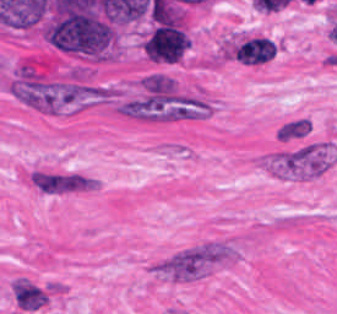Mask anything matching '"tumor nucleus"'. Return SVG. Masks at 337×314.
<instances>
[{
    "mask_svg": "<svg viewBox=\"0 0 337 314\" xmlns=\"http://www.w3.org/2000/svg\"><path fill=\"white\" fill-rule=\"evenodd\" d=\"M190 41L178 24L172 20L162 22L149 36L144 53L158 62H177Z\"/></svg>",
    "mask_w": 337,
    "mask_h": 314,
    "instance_id": "obj_1",
    "label": "tumor nucleus"
},
{
    "mask_svg": "<svg viewBox=\"0 0 337 314\" xmlns=\"http://www.w3.org/2000/svg\"><path fill=\"white\" fill-rule=\"evenodd\" d=\"M14 298L22 310H36L48 300L44 291L27 281H14Z\"/></svg>",
    "mask_w": 337,
    "mask_h": 314,
    "instance_id": "obj_2",
    "label": "tumor nucleus"
}]
</instances>
